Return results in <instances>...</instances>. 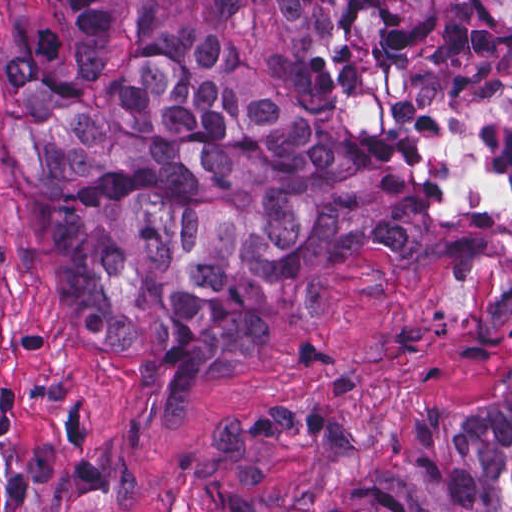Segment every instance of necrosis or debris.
Listing matches in <instances>:
<instances>
[{"label": "necrosis or debris", "instance_id": "1", "mask_svg": "<svg viewBox=\"0 0 512 512\" xmlns=\"http://www.w3.org/2000/svg\"><path fill=\"white\" fill-rule=\"evenodd\" d=\"M503 349L506 370L512 375V293L506 299L504 309Z\"/></svg>", "mask_w": 512, "mask_h": 512}]
</instances>
